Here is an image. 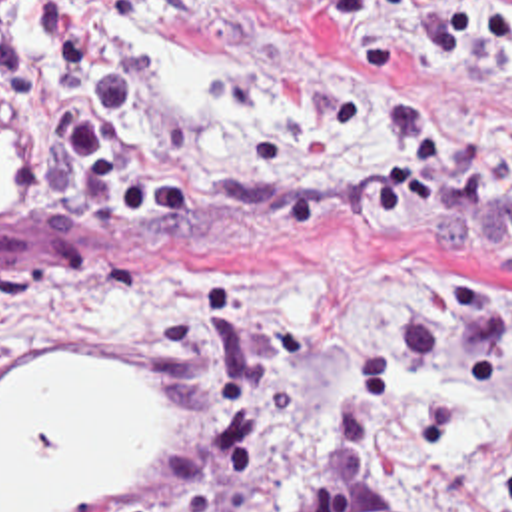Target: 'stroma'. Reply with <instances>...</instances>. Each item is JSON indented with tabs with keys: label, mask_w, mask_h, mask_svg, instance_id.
<instances>
[{
	"label": "stroma",
	"mask_w": 512,
	"mask_h": 512,
	"mask_svg": "<svg viewBox=\"0 0 512 512\" xmlns=\"http://www.w3.org/2000/svg\"><path fill=\"white\" fill-rule=\"evenodd\" d=\"M201 54L319 70L351 104L347 134L271 180L225 168L235 192L279 202L349 156L375 116V58L311 0H155L143 30ZM431 104L470 148L512 140V80L480 92L429 86ZM143 92L155 96L143 56ZM185 126V124H183ZM0 258L31 240L35 196L11 172ZM85 232L119 262V281L85 301L29 305L0 321V379L31 359H155L187 399V455L155 497L89 512H291L315 443L327 379L383 295L391 254L377 240L313 244L253 258L187 256L131 220L85 212ZM415 266L446 276H512L510 256H448ZM450 411L415 391L391 399L381 487L393 512H442L417 495L405 461L429 433L502 409Z\"/></svg>",
	"instance_id": "stroma-1"
}]
</instances>
